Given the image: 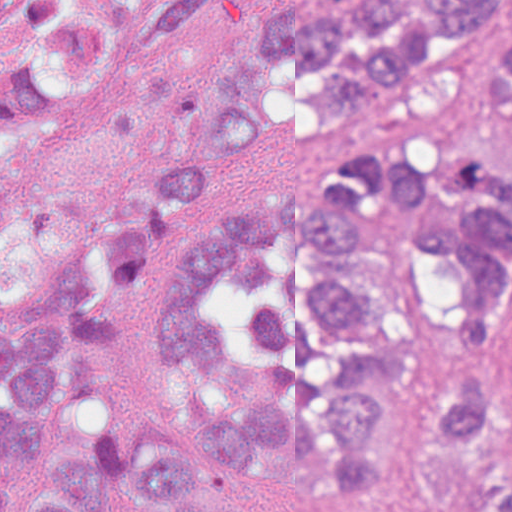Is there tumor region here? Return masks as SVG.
Masks as SVG:
<instances>
[{"label":"tumor region","instance_id":"tumor-region-1","mask_svg":"<svg viewBox=\"0 0 512 512\" xmlns=\"http://www.w3.org/2000/svg\"><path fill=\"white\" fill-rule=\"evenodd\" d=\"M213 1L183 0L149 47ZM509 6L311 0L259 22L164 200L228 196L254 146L301 122L326 182L229 208L190 246L160 252L141 218L102 232L8 313L0 277V512H251L283 490L382 504L400 378L452 512H512V166L455 129L465 65ZM118 44L112 0H0V145L97 84ZM481 84L512 101V32ZM141 296L186 441L143 457L119 426H79Z\"/></svg>","mask_w":512,"mask_h":512}]
</instances>
